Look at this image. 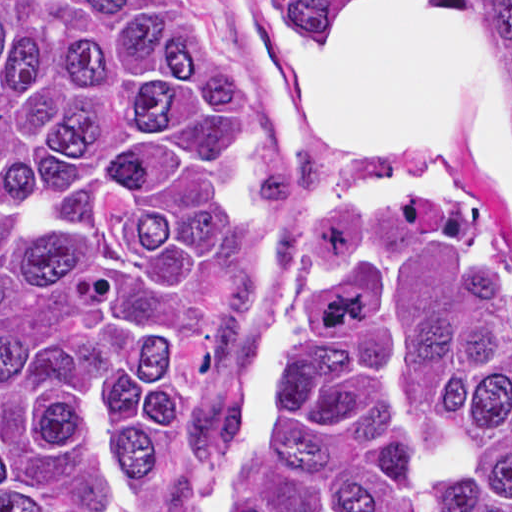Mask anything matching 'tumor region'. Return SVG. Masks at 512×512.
Masks as SVG:
<instances>
[{
  "mask_svg": "<svg viewBox=\"0 0 512 512\" xmlns=\"http://www.w3.org/2000/svg\"><path fill=\"white\" fill-rule=\"evenodd\" d=\"M510 73L512 1H491ZM357 1H282L336 40ZM254 104L183 1H0V512H512V278L468 198L312 214L244 406L251 284L320 186L241 155Z\"/></svg>",
  "mask_w": 512,
  "mask_h": 512,
  "instance_id": "e687c5a6",
  "label": "tumor region"
}]
</instances>
